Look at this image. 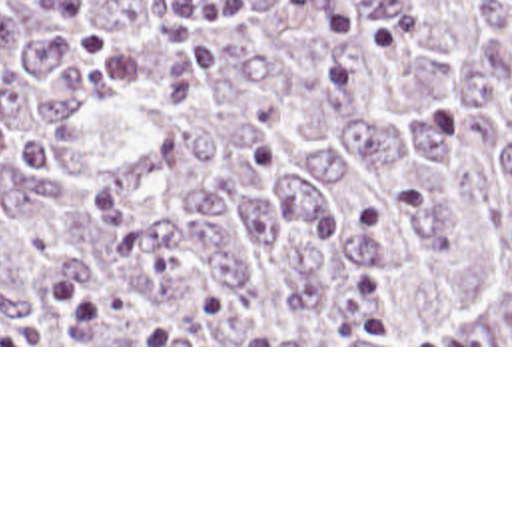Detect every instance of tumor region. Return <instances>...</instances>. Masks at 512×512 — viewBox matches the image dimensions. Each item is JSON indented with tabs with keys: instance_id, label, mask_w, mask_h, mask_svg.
I'll list each match as a JSON object with an SVG mask.
<instances>
[{
	"instance_id": "1",
	"label": "tumor region",
	"mask_w": 512,
	"mask_h": 512,
	"mask_svg": "<svg viewBox=\"0 0 512 512\" xmlns=\"http://www.w3.org/2000/svg\"><path fill=\"white\" fill-rule=\"evenodd\" d=\"M0 345H512V0H0Z\"/></svg>"
}]
</instances>
